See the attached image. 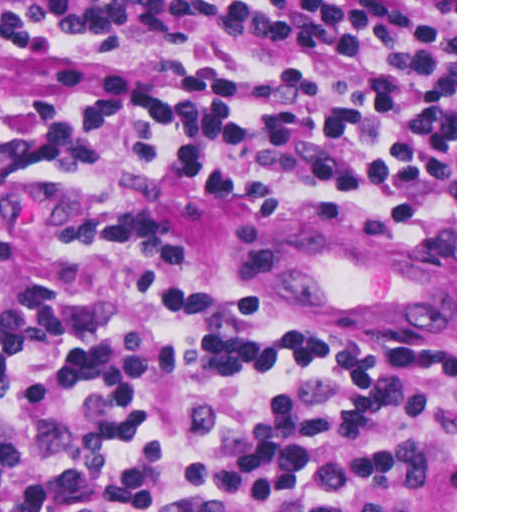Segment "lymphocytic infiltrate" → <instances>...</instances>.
I'll return each instance as SVG.
<instances>
[{
    "instance_id": "f902f5d3",
    "label": "lymphocytic infiltrate",
    "mask_w": 512,
    "mask_h": 512,
    "mask_svg": "<svg viewBox=\"0 0 512 512\" xmlns=\"http://www.w3.org/2000/svg\"><path fill=\"white\" fill-rule=\"evenodd\" d=\"M265 34L281 87L0 68V168L238 215L455 190V1H0V34ZM0 512H455V308L263 312L162 227L0 278Z\"/></svg>"
}]
</instances>
